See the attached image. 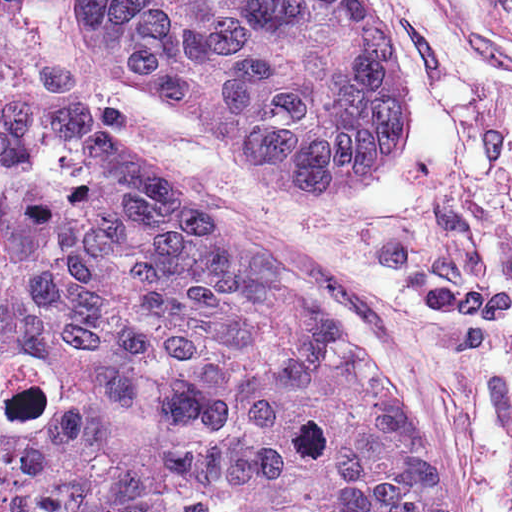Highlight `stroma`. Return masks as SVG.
<instances>
[{
  "label": "stroma",
  "mask_w": 512,
  "mask_h": 512,
  "mask_svg": "<svg viewBox=\"0 0 512 512\" xmlns=\"http://www.w3.org/2000/svg\"><path fill=\"white\" fill-rule=\"evenodd\" d=\"M410 88L409 146L341 207L266 191L228 132L116 71L85 0L0 16V95L54 101L158 169L342 328L417 430L449 512H512V65L418 0H373Z\"/></svg>",
  "instance_id": "stroma-1"
}]
</instances>
